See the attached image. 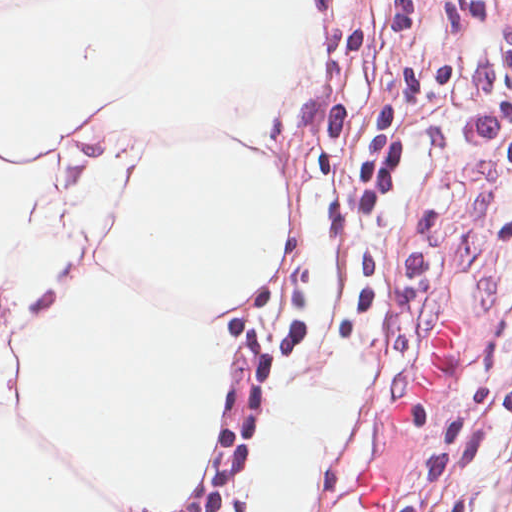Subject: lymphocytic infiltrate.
<instances>
[{"label": "lymphocytic infiltrate", "mask_w": 512, "mask_h": 512, "mask_svg": "<svg viewBox=\"0 0 512 512\" xmlns=\"http://www.w3.org/2000/svg\"><path fill=\"white\" fill-rule=\"evenodd\" d=\"M484 60L493 133L512 170V0H409ZM498 334V356L512 377V287Z\"/></svg>", "instance_id": "1"}]
</instances>
